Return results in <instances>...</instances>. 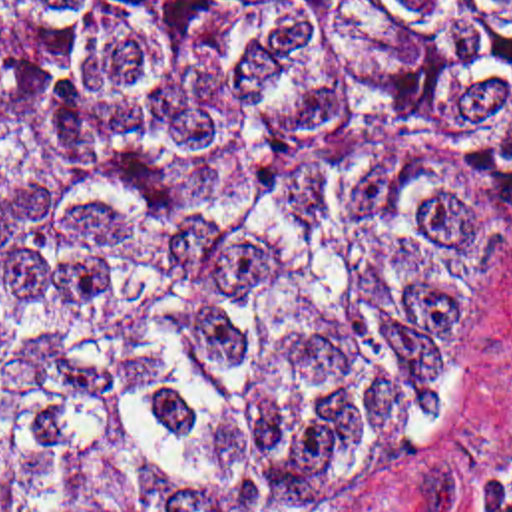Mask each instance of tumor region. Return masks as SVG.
Returning <instances> with one entry per match:
<instances>
[{
  "label": "tumor region",
  "instance_id": "obj_1",
  "mask_svg": "<svg viewBox=\"0 0 512 512\" xmlns=\"http://www.w3.org/2000/svg\"><path fill=\"white\" fill-rule=\"evenodd\" d=\"M512 227V0H0V512H368Z\"/></svg>",
  "mask_w": 512,
  "mask_h": 512
}]
</instances>
